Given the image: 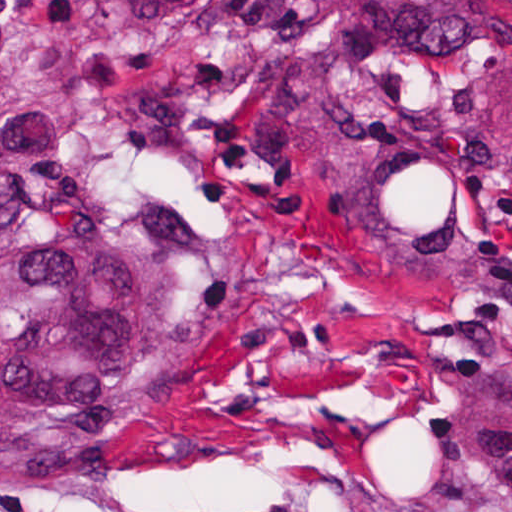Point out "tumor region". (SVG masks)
Masks as SVG:
<instances>
[{
	"label": "tumor region",
	"instance_id": "e687c5a6",
	"mask_svg": "<svg viewBox=\"0 0 512 512\" xmlns=\"http://www.w3.org/2000/svg\"><path fill=\"white\" fill-rule=\"evenodd\" d=\"M462 108L512 112V0H0V477L98 473L294 323L153 187L155 118L234 190L512 302Z\"/></svg>",
	"mask_w": 512,
	"mask_h": 512
}]
</instances>
